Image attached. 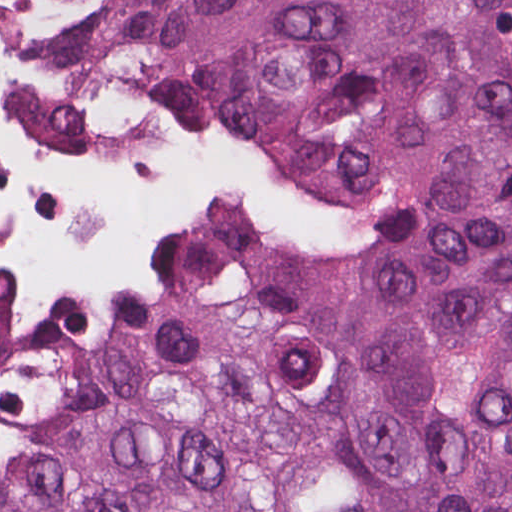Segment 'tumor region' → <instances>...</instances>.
Here are the masks:
<instances>
[{"label":"tumor region","mask_w":512,"mask_h":512,"mask_svg":"<svg viewBox=\"0 0 512 512\" xmlns=\"http://www.w3.org/2000/svg\"><path fill=\"white\" fill-rule=\"evenodd\" d=\"M132 89L379 219L374 248H266L297 307L512 328V0H179ZM28 458L0 512H512V351L358 340L153 248L127 311L41 300L0 373Z\"/></svg>","instance_id":"tumor-region-1"}]
</instances>
